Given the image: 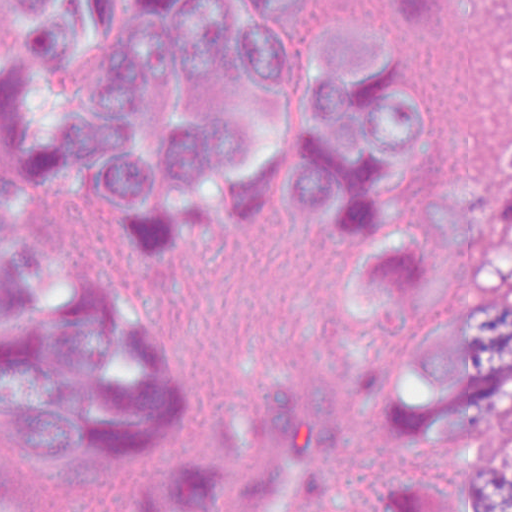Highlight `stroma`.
I'll return each instance as SVG.
<instances>
[{
    "label": "stroma",
    "mask_w": 512,
    "mask_h": 512,
    "mask_svg": "<svg viewBox=\"0 0 512 512\" xmlns=\"http://www.w3.org/2000/svg\"><path fill=\"white\" fill-rule=\"evenodd\" d=\"M402 316L377 305V431L393 489H464L475 469L512 475V420L492 401L410 430L393 417L385 375Z\"/></svg>",
    "instance_id": "stroma-1"
}]
</instances>
